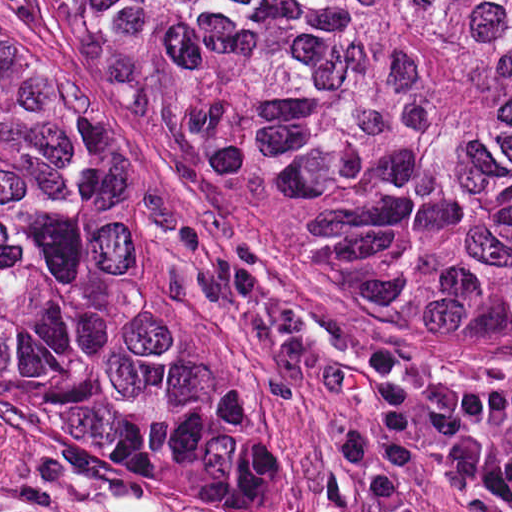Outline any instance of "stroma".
Instances as JSON below:
<instances>
[{
	"label": "stroma",
	"mask_w": 512,
	"mask_h": 512,
	"mask_svg": "<svg viewBox=\"0 0 512 512\" xmlns=\"http://www.w3.org/2000/svg\"><path fill=\"white\" fill-rule=\"evenodd\" d=\"M0 512H269L0 424Z\"/></svg>",
	"instance_id": "1"
}]
</instances>
